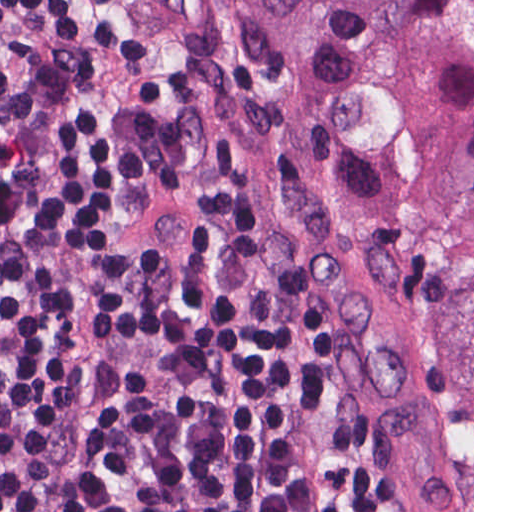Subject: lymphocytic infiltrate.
Returning a JSON list of instances; mask_svg holds the SVG:
<instances>
[{
	"instance_id": "f902f5d3",
	"label": "lymphocytic infiltrate",
	"mask_w": 512,
	"mask_h": 512,
	"mask_svg": "<svg viewBox=\"0 0 512 512\" xmlns=\"http://www.w3.org/2000/svg\"><path fill=\"white\" fill-rule=\"evenodd\" d=\"M0 512H430L249 185L99 0H0Z\"/></svg>"
}]
</instances>
